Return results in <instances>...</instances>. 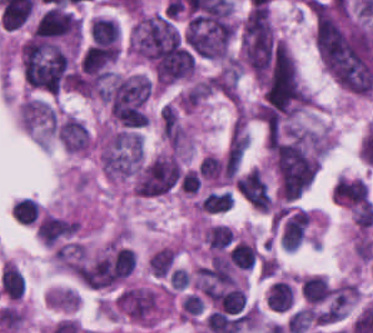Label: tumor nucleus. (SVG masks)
Wrapping results in <instances>:
<instances>
[{
	"instance_id": "1",
	"label": "tumor nucleus",
	"mask_w": 373,
	"mask_h": 333,
	"mask_svg": "<svg viewBox=\"0 0 373 333\" xmlns=\"http://www.w3.org/2000/svg\"><path fill=\"white\" fill-rule=\"evenodd\" d=\"M273 162L279 194L291 200L311 185L319 167L302 135L274 143Z\"/></svg>"
},
{
	"instance_id": "2",
	"label": "tumor nucleus",
	"mask_w": 373,
	"mask_h": 333,
	"mask_svg": "<svg viewBox=\"0 0 373 333\" xmlns=\"http://www.w3.org/2000/svg\"><path fill=\"white\" fill-rule=\"evenodd\" d=\"M237 188L242 197L254 208L269 210L267 184L258 168H251L238 180Z\"/></svg>"
},
{
	"instance_id": "3",
	"label": "tumor nucleus",
	"mask_w": 373,
	"mask_h": 333,
	"mask_svg": "<svg viewBox=\"0 0 373 333\" xmlns=\"http://www.w3.org/2000/svg\"><path fill=\"white\" fill-rule=\"evenodd\" d=\"M57 136L68 151H83L88 148L89 135L83 123L68 114L58 118Z\"/></svg>"
},
{
	"instance_id": "4",
	"label": "tumor nucleus",
	"mask_w": 373,
	"mask_h": 333,
	"mask_svg": "<svg viewBox=\"0 0 373 333\" xmlns=\"http://www.w3.org/2000/svg\"><path fill=\"white\" fill-rule=\"evenodd\" d=\"M211 91L228 97H238V69L232 66H224L208 80Z\"/></svg>"
},
{
	"instance_id": "5",
	"label": "tumor nucleus",
	"mask_w": 373,
	"mask_h": 333,
	"mask_svg": "<svg viewBox=\"0 0 373 333\" xmlns=\"http://www.w3.org/2000/svg\"><path fill=\"white\" fill-rule=\"evenodd\" d=\"M162 134L168 145L175 150L179 148L183 138V127L173 106L164 104L160 114Z\"/></svg>"
}]
</instances>
